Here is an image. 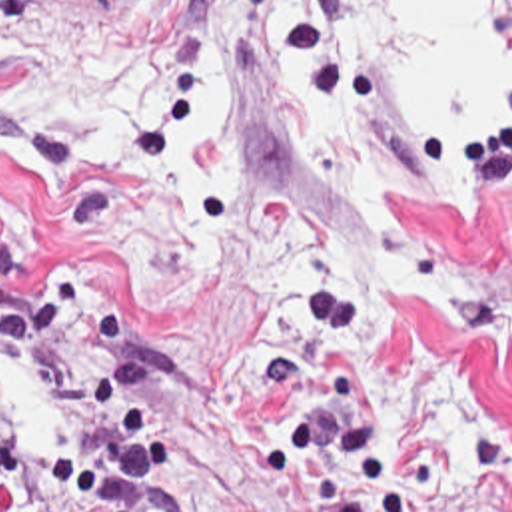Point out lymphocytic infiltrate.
Segmentation results:
<instances>
[{
  "mask_svg": "<svg viewBox=\"0 0 512 512\" xmlns=\"http://www.w3.org/2000/svg\"><path fill=\"white\" fill-rule=\"evenodd\" d=\"M5 358L35 390L77 396L57 434L0 430V512H155L163 496L159 368L111 286H55L1 306ZM265 420L261 488L307 512H512V442L464 422L450 460L401 454L351 296L293 302L291 348L251 372Z\"/></svg>",
  "mask_w": 512,
  "mask_h": 512,
  "instance_id": "lymphocytic-infiltrate-1",
  "label": "lymphocytic infiltrate"
}]
</instances>
